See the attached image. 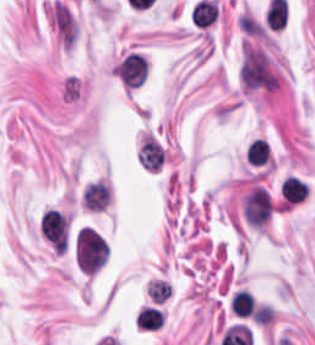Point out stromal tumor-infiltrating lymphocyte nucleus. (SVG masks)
<instances>
[{"instance_id":"3290ff9b","label":"stromal tumor-infiltrating lymphocyte nucleus","mask_w":315,"mask_h":345,"mask_svg":"<svg viewBox=\"0 0 315 345\" xmlns=\"http://www.w3.org/2000/svg\"><path fill=\"white\" fill-rule=\"evenodd\" d=\"M113 74L127 89H135L147 76L145 59L141 53L128 52L113 66Z\"/></svg>"},{"instance_id":"52c7bb5b","label":"stromal tumor-infiltrating lymphocyte nucleus","mask_w":315,"mask_h":345,"mask_svg":"<svg viewBox=\"0 0 315 345\" xmlns=\"http://www.w3.org/2000/svg\"><path fill=\"white\" fill-rule=\"evenodd\" d=\"M113 201V188L104 176L90 178L79 191L80 208L86 213H106Z\"/></svg>"},{"instance_id":"abfb95fc","label":"stromal tumor-infiltrating lymphocyte nucleus","mask_w":315,"mask_h":345,"mask_svg":"<svg viewBox=\"0 0 315 345\" xmlns=\"http://www.w3.org/2000/svg\"><path fill=\"white\" fill-rule=\"evenodd\" d=\"M42 235L55 247L68 244V220L59 210L47 209L40 219Z\"/></svg>"},{"instance_id":"bc302bb0","label":"stromal tumor-infiltrating lymphocyte nucleus","mask_w":315,"mask_h":345,"mask_svg":"<svg viewBox=\"0 0 315 345\" xmlns=\"http://www.w3.org/2000/svg\"><path fill=\"white\" fill-rule=\"evenodd\" d=\"M73 255L78 269L95 273L108 257L106 239L96 230L81 226L74 234Z\"/></svg>"},{"instance_id":"4f13568d","label":"stromal tumor-infiltrating lymphocyte nucleus","mask_w":315,"mask_h":345,"mask_svg":"<svg viewBox=\"0 0 315 345\" xmlns=\"http://www.w3.org/2000/svg\"><path fill=\"white\" fill-rule=\"evenodd\" d=\"M165 315L157 306L144 305L135 317V323L140 328L157 329L164 322Z\"/></svg>"},{"instance_id":"2a367800","label":"stromal tumor-infiltrating lymphocyte nucleus","mask_w":315,"mask_h":345,"mask_svg":"<svg viewBox=\"0 0 315 345\" xmlns=\"http://www.w3.org/2000/svg\"><path fill=\"white\" fill-rule=\"evenodd\" d=\"M229 308L238 316H249L254 311L253 295L245 290H237L229 301Z\"/></svg>"},{"instance_id":"4803ca6d","label":"stromal tumor-infiltrating lymphocyte nucleus","mask_w":315,"mask_h":345,"mask_svg":"<svg viewBox=\"0 0 315 345\" xmlns=\"http://www.w3.org/2000/svg\"><path fill=\"white\" fill-rule=\"evenodd\" d=\"M268 153L269 143L257 137L251 139L246 149L248 163L256 166L268 160Z\"/></svg>"},{"instance_id":"9ea309e8","label":"stromal tumor-infiltrating lymphocyte nucleus","mask_w":315,"mask_h":345,"mask_svg":"<svg viewBox=\"0 0 315 345\" xmlns=\"http://www.w3.org/2000/svg\"><path fill=\"white\" fill-rule=\"evenodd\" d=\"M137 155L139 162L144 167L157 170L162 161L163 147L155 137L149 134L143 138Z\"/></svg>"},{"instance_id":"f3e2335f","label":"stromal tumor-infiltrating lymphocyte nucleus","mask_w":315,"mask_h":345,"mask_svg":"<svg viewBox=\"0 0 315 345\" xmlns=\"http://www.w3.org/2000/svg\"><path fill=\"white\" fill-rule=\"evenodd\" d=\"M307 191V183L295 175H288L282 180L280 192L286 203L292 204L300 201Z\"/></svg>"}]
</instances>
